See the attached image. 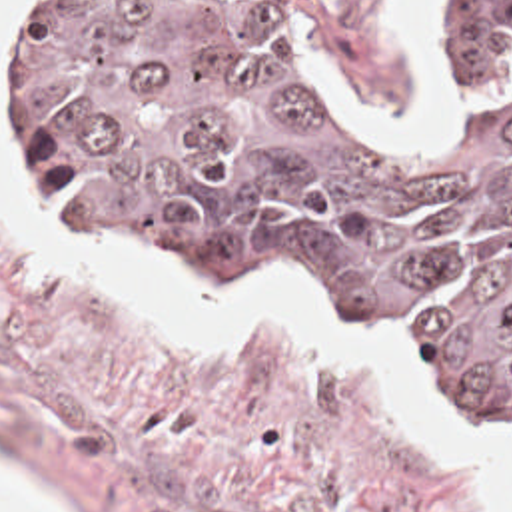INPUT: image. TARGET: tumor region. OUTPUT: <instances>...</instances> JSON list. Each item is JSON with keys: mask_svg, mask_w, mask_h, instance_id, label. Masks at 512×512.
<instances>
[{"mask_svg": "<svg viewBox=\"0 0 512 512\" xmlns=\"http://www.w3.org/2000/svg\"><path fill=\"white\" fill-rule=\"evenodd\" d=\"M419 42L455 90L437 144L381 130L277 0H22L10 186L136 274L313 296L512 448L505 0H429Z\"/></svg>", "mask_w": 512, "mask_h": 512, "instance_id": "e687c5a6", "label": "tumor region"}]
</instances>
